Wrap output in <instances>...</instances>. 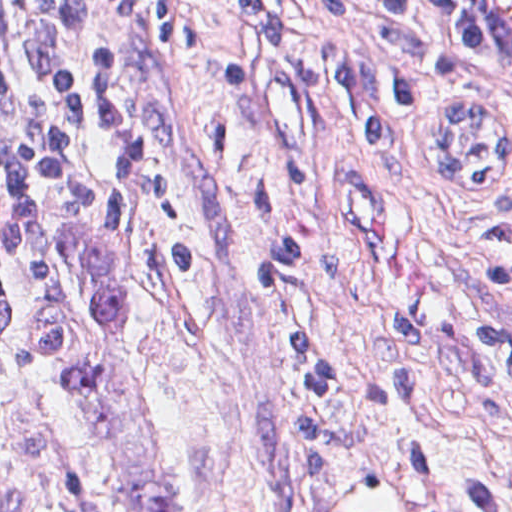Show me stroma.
Instances as JSON below:
<instances>
[{
    "mask_svg": "<svg viewBox=\"0 0 512 512\" xmlns=\"http://www.w3.org/2000/svg\"><path fill=\"white\" fill-rule=\"evenodd\" d=\"M512 130V87L467 40L457 0H424ZM229 23L201 15L190 51L153 63L160 157L182 217L119 181L101 129L84 0L43 26V94L90 171L38 228L0 346V512H305L288 404L305 391L290 331L322 319L320 375L344 422L333 512H512V291L479 248L512 202V162L485 191H451L446 111L382 135L354 106L208 80ZM298 161L310 184L262 208L260 183ZM104 228L126 288L112 367L61 390L109 330L96 315L86 234ZM192 240L199 283L159 274ZM287 243L323 246V272L258 286ZM299 477L305 487L299 438Z\"/></svg>",
    "mask_w": 512,
    "mask_h": 512,
    "instance_id": "stroma-1",
    "label": "stroma"
}]
</instances>
